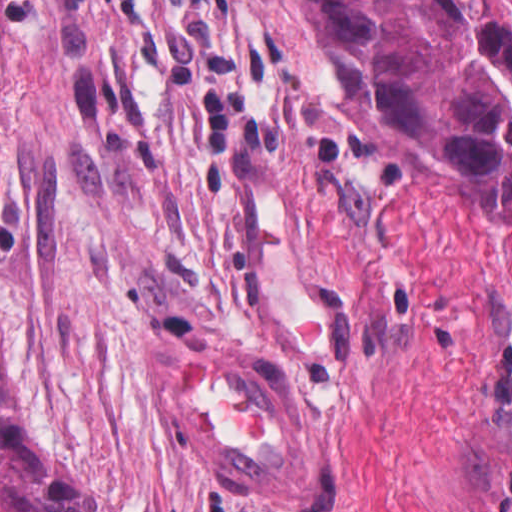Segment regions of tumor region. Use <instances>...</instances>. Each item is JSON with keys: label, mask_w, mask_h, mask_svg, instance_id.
Instances as JSON below:
<instances>
[{"label": "tumor region", "mask_w": 512, "mask_h": 512, "mask_svg": "<svg viewBox=\"0 0 512 512\" xmlns=\"http://www.w3.org/2000/svg\"><path fill=\"white\" fill-rule=\"evenodd\" d=\"M326 73L378 134L512 224V0H296ZM7 0H0V85ZM0 512H97L32 453L0 370Z\"/></svg>", "instance_id": "obj_1"}]
</instances>
